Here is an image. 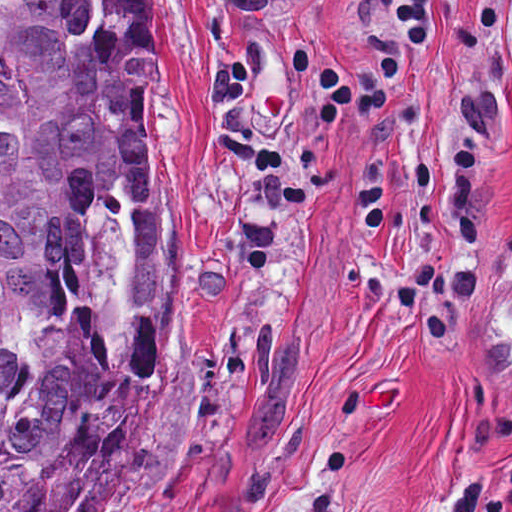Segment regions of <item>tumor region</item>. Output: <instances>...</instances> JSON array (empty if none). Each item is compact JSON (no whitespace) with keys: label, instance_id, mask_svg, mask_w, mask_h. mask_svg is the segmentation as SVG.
I'll use <instances>...</instances> for the list:
<instances>
[{"label":"tumor region","instance_id":"e687c5a6","mask_svg":"<svg viewBox=\"0 0 512 512\" xmlns=\"http://www.w3.org/2000/svg\"><path fill=\"white\" fill-rule=\"evenodd\" d=\"M183 304L146 0H0V512H104Z\"/></svg>","mask_w":512,"mask_h":512}]
</instances>
